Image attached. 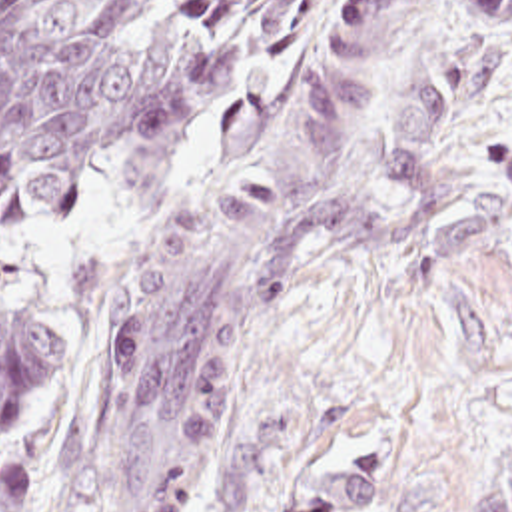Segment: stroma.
I'll use <instances>...</instances> for the list:
<instances>
[{"instance_id": "35a3bbf8", "label": "stroma", "mask_w": 512, "mask_h": 512, "mask_svg": "<svg viewBox=\"0 0 512 512\" xmlns=\"http://www.w3.org/2000/svg\"><path fill=\"white\" fill-rule=\"evenodd\" d=\"M349 2H321L289 60L213 118L165 190L123 168L57 228L0 230V296L41 308L71 340L65 382L25 431L0 439V471L31 477L33 512L131 511L173 453L201 475L183 512H299V487L349 457L384 467L369 512H470L476 469L512 447V26L460 100L422 202L382 170L406 68L426 44L474 48L476 28L466 0H414L331 188L370 222L416 232L303 284L245 362L219 427L171 431L105 475H77L79 350L95 292L271 144Z\"/></svg>"}]
</instances>
